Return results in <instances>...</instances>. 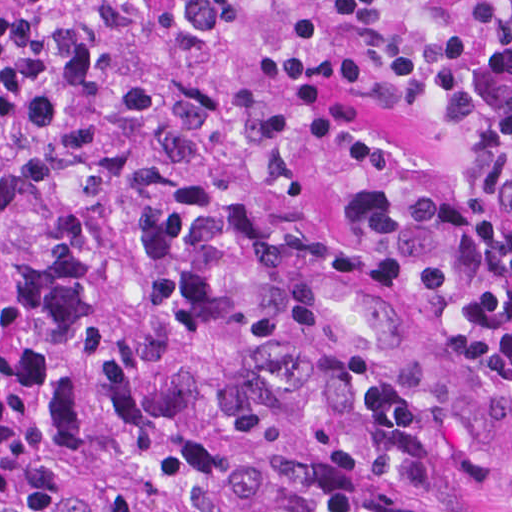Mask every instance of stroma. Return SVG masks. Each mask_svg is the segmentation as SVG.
Here are the masks:
<instances>
[{"instance_id":"stroma-1","label":"stroma","mask_w":512,"mask_h":512,"mask_svg":"<svg viewBox=\"0 0 512 512\" xmlns=\"http://www.w3.org/2000/svg\"><path fill=\"white\" fill-rule=\"evenodd\" d=\"M334 192H446L506 209L481 184L464 133L419 111H389L353 148L295 153L203 185H136L0 171V233L32 245L64 217H118L202 201H294Z\"/></svg>"}]
</instances>
